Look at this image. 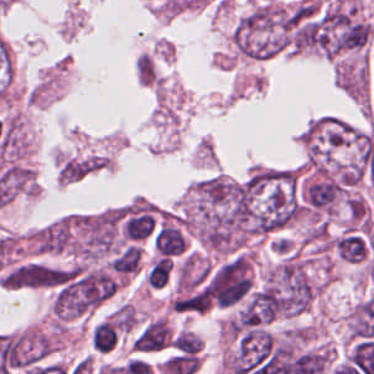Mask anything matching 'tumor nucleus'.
I'll use <instances>...</instances> for the list:
<instances>
[{"mask_svg": "<svg viewBox=\"0 0 374 374\" xmlns=\"http://www.w3.org/2000/svg\"><path fill=\"white\" fill-rule=\"evenodd\" d=\"M170 341L169 329L161 320L157 318L148 325L136 337L132 346L133 350H153L164 348Z\"/></svg>", "mask_w": 374, "mask_h": 374, "instance_id": "4", "label": "tumor nucleus"}, {"mask_svg": "<svg viewBox=\"0 0 374 374\" xmlns=\"http://www.w3.org/2000/svg\"><path fill=\"white\" fill-rule=\"evenodd\" d=\"M185 225L205 250L221 255L242 251L252 237L245 179L220 174L194 186L185 202Z\"/></svg>", "mask_w": 374, "mask_h": 374, "instance_id": "1", "label": "tumor nucleus"}, {"mask_svg": "<svg viewBox=\"0 0 374 374\" xmlns=\"http://www.w3.org/2000/svg\"><path fill=\"white\" fill-rule=\"evenodd\" d=\"M171 347L174 354L199 355L201 352V337L189 329L174 332Z\"/></svg>", "mask_w": 374, "mask_h": 374, "instance_id": "5", "label": "tumor nucleus"}, {"mask_svg": "<svg viewBox=\"0 0 374 374\" xmlns=\"http://www.w3.org/2000/svg\"><path fill=\"white\" fill-rule=\"evenodd\" d=\"M237 187L247 234L278 230L302 214L298 178L289 169H257Z\"/></svg>", "mask_w": 374, "mask_h": 374, "instance_id": "2", "label": "tumor nucleus"}, {"mask_svg": "<svg viewBox=\"0 0 374 374\" xmlns=\"http://www.w3.org/2000/svg\"><path fill=\"white\" fill-rule=\"evenodd\" d=\"M313 281L302 257L286 255L267 267L255 287L256 302L274 319L306 310Z\"/></svg>", "mask_w": 374, "mask_h": 374, "instance_id": "3", "label": "tumor nucleus"}]
</instances>
